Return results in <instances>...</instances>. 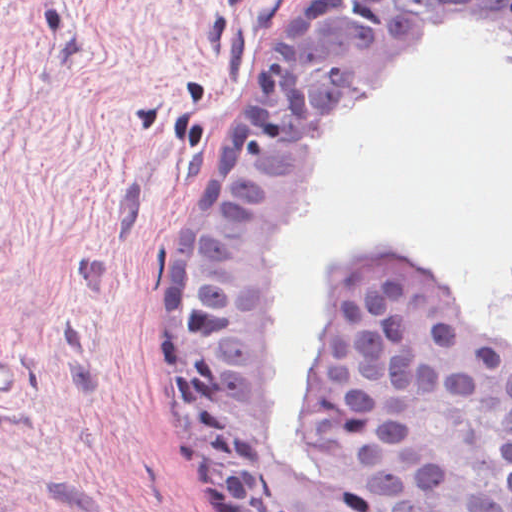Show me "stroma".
Returning a JSON list of instances; mask_svg holds the SVG:
<instances>
[{"instance_id": "obj_1", "label": "stroma", "mask_w": 512, "mask_h": 512, "mask_svg": "<svg viewBox=\"0 0 512 512\" xmlns=\"http://www.w3.org/2000/svg\"><path fill=\"white\" fill-rule=\"evenodd\" d=\"M296 0H0V512H240L162 367L175 193Z\"/></svg>"}]
</instances>
